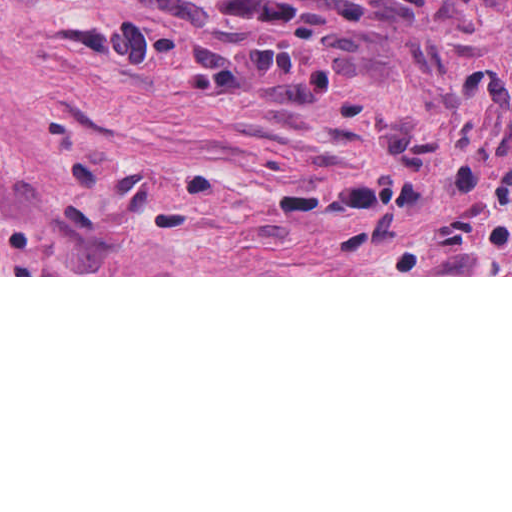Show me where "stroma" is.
<instances>
[{"label": "stroma", "mask_w": 512, "mask_h": 512, "mask_svg": "<svg viewBox=\"0 0 512 512\" xmlns=\"http://www.w3.org/2000/svg\"><path fill=\"white\" fill-rule=\"evenodd\" d=\"M0 277H512V0H0Z\"/></svg>", "instance_id": "1"}]
</instances>
